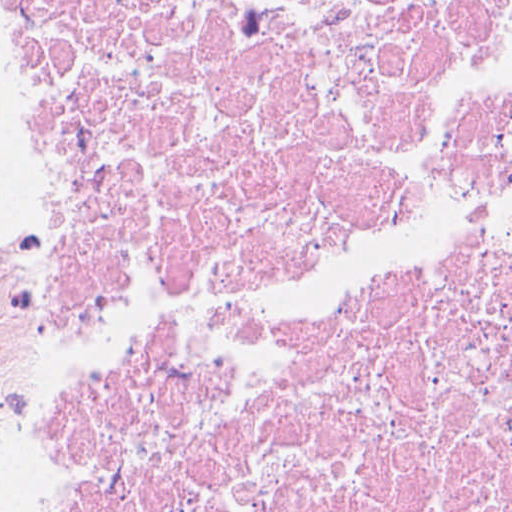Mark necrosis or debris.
Returning <instances> with one entry per match:
<instances>
[{"label":"necrosis or debris","mask_w":512,"mask_h":512,"mask_svg":"<svg viewBox=\"0 0 512 512\" xmlns=\"http://www.w3.org/2000/svg\"><path fill=\"white\" fill-rule=\"evenodd\" d=\"M60 307L211 334L409 221L512 103V0H7ZM22 512H512V131L438 252L60 412Z\"/></svg>","instance_id":"1"}]
</instances>
